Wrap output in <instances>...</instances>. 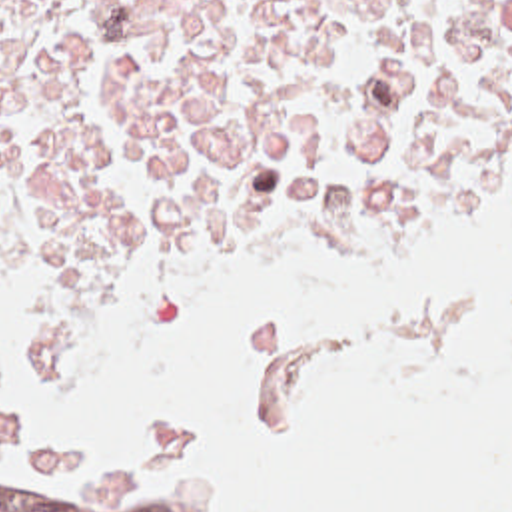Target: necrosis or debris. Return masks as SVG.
<instances>
[{
    "instance_id": "4bbe7bcc",
    "label": "necrosis or debris",
    "mask_w": 512,
    "mask_h": 512,
    "mask_svg": "<svg viewBox=\"0 0 512 512\" xmlns=\"http://www.w3.org/2000/svg\"><path fill=\"white\" fill-rule=\"evenodd\" d=\"M512 160V0H0V246L113 336L257 232L352 272Z\"/></svg>"
}]
</instances>
